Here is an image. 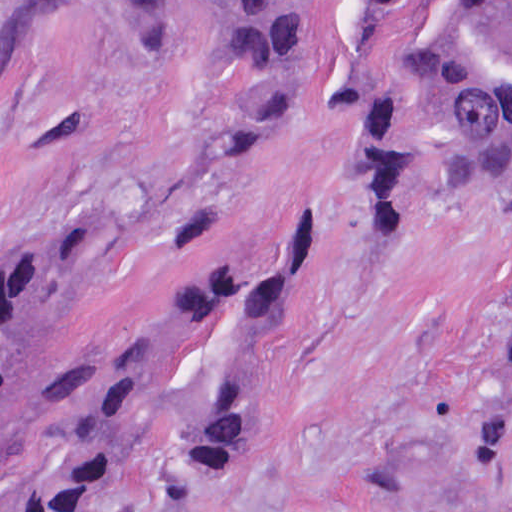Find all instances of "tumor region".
<instances>
[{
    "mask_svg": "<svg viewBox=\"0 0 512 512\" xmlns=\"http://www.w3.org/2000/svg\"><path fill=\"white\" fill-rule=\"evenodd\" d=\"M87 0H0V71L43 48ZM150 31L154 0H105ZM329 0H222L220 38L231 60L280 59L312 13ZM372 46H383L442 99L477 169L512 146V0H355ZM241 207L188 212L154 236L109 253L103 287L159 234H188ZM320 232L308 212L284 217L261 261L228 240L189 275L156 323L131 347L100 391L79 466L58 512H137L127 497L141 446L163 408L192 337L255 316L299 286L316 259ZM93 228L47 229L0 277V490L26 465L52 389L59 306L89 256ZM270 374L217 373L167 443L145 512H179L203 468L255 422ZM508 487H474L456 512H506Z\"/></svg>",
    "mask_w": 512,
    "mask_h": 512,
    "instance_id": "tumor-region-1",
    "label": "tumor region"
}]
</instances>
